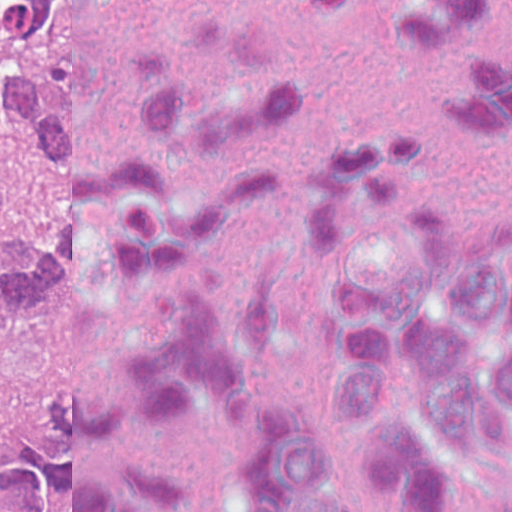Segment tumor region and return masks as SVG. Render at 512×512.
Wrapping results in <instances>:
<instances>
[{
  "label": "tumor region",
  "instance_id": "e687c5a6",
  "mask_svg": "<svg viewBox=\"0 0 512 512\" xmlns=\"http://www.w3.org/2000/svg\"><path fill=\"white\" fill-rule=\"evenodd\" d=\"M72 261L60 0H0V512L47 487Z\"/></svg>",
  "mask_w": 512,
  "mask_h": 512
}]
</instances>
